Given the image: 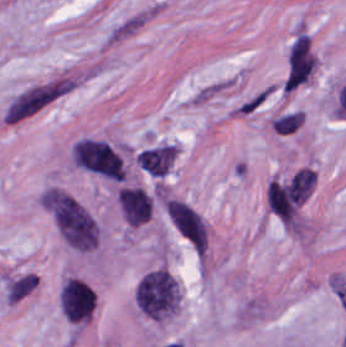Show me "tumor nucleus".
<instances>
[{
    "instance_id": "7",
    "label": "tumor nucleus",
    "mask_w": 346,
    "mask_h": 347,
    "mask_svg": "<svg viewBox=\"0 0 346 347\" xmlns=\"http://www.w3.org/2000/svg\"><path fill=\"white\" fill-rule=\"evenodd\" d=\"M177 152L170 143H163L137 152V165L153 176H164L172 165Z\"/></svg>"
},
{
    "instance_id": "6",
    "label": "tumor nucleus",
    "mask_w": 346,
    "mask_h": 347,
    "mask_svg": "<svg viewBox=\"0 0 346 347\" xmlns=\"http://www.w3.org/2000/svg\"><path fill=\"white\" fill-rule=\"evenodd\" d=\"M117 203L127 225L136 227L151 217L152 201L142 188L120 187Z\"/></svg>"
},
{
    "instance_id": "2",
    "label": "tumor nucleus",
    "mask_w": 346,
    "mask_h": 347,
    "mask_svg": "<svg viewBox=\"0 0 346 347\" xmlns=\"http://www.w3.org/2000/svg\"><path fill=\"white\" fill-rule=\"evenodd\" d=\"M133 299L147 317L162 320L177 313L180 287L167 267L143 274L133 292Z\"/></svg>"
},
{
    "instance_id": "5",
    "label": "tumor nucleus",
    "mask_w": 346,
    "mask_h": 347,
    "mask_svg": "<svg viewBox=\"0 0 346 347\" xmlns=\"http://www.w3.org/2000/svg\"><path fill=\"white\" fill-rule=\"evenodd\" d=\"M167 216L171 225L201 255L206 245V223L197 210L183 200L168 198Z\"/></svg>"
},
{
    "instance_id": "3",
    "label": "tumor nucleus",
    "mask_w": 346,
    "mask_h": 347,
    "mask_svg": "<svg viewBox=\"0 0 346 347\" xmlns=\"http://www.w3.org/2000/svg\"><path fill=\"white\" fill-rule=\"evenodd\" d=\"M72 158L82 169L111 179L126 180L123 157L110 141L82 137L72 147Z\"/></svg>"
},
{
    "instance_id": "4",
    "label": "tumor nucleus",
    "mask_w": 346,
    "mask_h": 347,
    "mask_svg": "<svg viewBox=\"0 0 346 347\" xmlns=\"http://www.w3.org/2000/svg\"><path fill=\"white\" fill-rule=\"evenodd\" d=\"M59 307L72 324L90 321L95 312L91 286L83 280L65 277L60 288Z\"/></svg>"
},
{
    "instance_id": "1",
    "label": "tumor nucleus",
    "mask_w": 346,
    "mask_h": 347,
    "mask_svg": "<svg viewBox=\"0 0 346 347\" xmlns=\"http://www.w3.org/2000/svg\"><path fill=\"white\" fill-rule=\"evenodd\" d=\"M50 212L61 239L72 249L90 252L100 242L98 220L66 190L53 188Z\"/></svg>"
}]
</instances>
